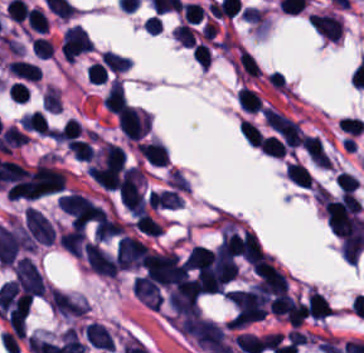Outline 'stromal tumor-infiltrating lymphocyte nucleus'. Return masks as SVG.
I'll use <instances>...</instances> for the list:
<instances>
[{"mask_svg":"<svg viewBox=\"0 0 364 353\" xmlns=\"http://www.w3.org/2000/svg\"><path fill=\"white\" fill-rule=\"evenodd\" d=\"M8 70L13 75L27 81L35 82L42 77L41 69L37 64L22 59L9 61Z\"/></svg>","mask_w":364,"mask_h":353,"instance_id":"4f13568d","label":"stromal tumor-infiltrating lymphocyte nucleus"},{"mask_svg":"<svg viewBox=\"0 0 364 353\" xmlns=\"http://www.w3.org/2000/svg\"><path fill=\"white\" fill-rule=\"evenodd\" d=\"M286 177L300 187L311 188L312 186V176L302 163L288 162Z\"/></svg>","mask_w":364,"mask_h":353,"instance_id":"2a367800","label":"stromal tumor-infiltrating lymphocyte nucleus"},{"mask_svg":"<svg viewBox=\"0 0 364 353\" xmlns=\"http://www.w3.org/2000/svg\"><path fill=\"white\" fill-rule=\"evenodd\" d=\"M172 34L186 47H193L196 43L195 31L187 23H180Z\"/></svg>","mask_w":364,"mask_h":353,"instance_id":"04cf8593","label":"stromal tumor-infiltrating lymphocyte nucleus"},{"mask_svg":"<svg viewBox=\"0 0 364 353\" xmlns=\"http://www.w3.org/2000/svg\"><path fill=\"white\" fill-rule=\"evenodd\" d=\"M123 229V223L101 209L95 226L96 240H105L123 234Z\"/></svg>","mask_w":364,"mask_h":353,"instance_id":"9ea309e8","label":"stromal tumor-infiltrating lymphocyte nucleus"},{"mask_svg":"<svg viewBox=\"0 0 364 353\" xmlns=\"http://www.w3.org/2000/svg\"><path fill=\"white\" fill-rule=\"evenodd\" d=\"M57 241L66 252L80 258L85 241V232L81 228L74 227L58 235Z\"/></svg>","mask_w":364,"mask_h":353,"instance_id":"f3e2335f","label":"stromal tumor-infiltrating lymphocyte nucleus"},{"mask_svg":"<svg viewBox=\"0 0 364 353\" xmlns=\"http://www.w3.org/2000/svg\"><path fill=\"white\" fill-rule=\"evenodd\" d=\"M93 43L82 26H69L65 32L61 48L66 61H75L91 50Z\"/></svg>","mask_w":364,"mask_h":353,"instance_id":"bc302bb0","label":"stromal tumor-infiltrating lymphocyte nucleus"},{"mask_svg":"<svg viewBox=\"0 0 364 353\" xmlns=\"http://www.w3.org/2000/svg\"><path fill=\"white\" fill-rule=\"evenodd\" d=\"M26 22L36 32H46L47 21L41 8L31 7L27 12Z\"/></svg>","mask_w":364,"mask_h":353,"instance_id":"42bb06b2","label":"stromal tumor-infiltrating lymphocyte nucleus"},{"mask_svg":"<svg viewBox=\"0 0 364 353\" xmlns=\"http://www.w3.org/2000/svg\"><path fill=\"white\" fill-rule=\"evenodd\" d=\"M145 258V247L140 240L123 236L117 243L115 260L119 268L132 270L139 268Z\"/></svg>","mask_w":364,"mask_h":353,"instance_id":"52c7bb5b","label":"stromal tumor-infiltrating lymphocyte nucleus"},{"mask_svg":"<svg viewBox=\"0 0 364 353\" xmlns=\"http://www.w3.org/2000/svg\"><path fill=\"white\" fill-rule=\"evenodd\" d=\"M215 253L211 249L195 247L191 249L185 266L187 271L206 272L214 267Z\"/></svg>","mask_w":364,"mask_h":353,"instance_id":"abfb95fc","label":"stromal tumor-infiltrating lymphocyte nucleus"},{"mask_svg":"<svg viewBox=\"0 0 364 353\" xmlns=\"http://www.w3.org/2000/svg\"><path fill=\"white\" fill-rule=\"evenodd\" d=\"M310 24L323 38L338 42L342 34V20L335 13H315Z\"/></svg>","mask_w":364,"mask_h":353,"instance_id":"3290ff9b","label":"stromal tumor-infiltrating lymphocyte nucleus"},{"mask_svg":"<svg viewBox=\"0 0 364 353\" xmlns=\"http://www.w3.org/2000/svg\"><path fill=\"white\" fill-rule=\"evenodd\" d=\"M261 150L272 157H283L285 145L274 135L263 137L259 143Z\"/></svg>","mask_w":364,"mask_h":353,"instance_id":"3c572f05","label":"stromal tumor-infiltrating lymphocyte nucleus"},{"mask_svg":"<svg viewBox=\"0 0 364 353\" xmlns=\"http://www.w3.org/2000/svg\"><path fill=\"white\" fill-rule=\"evenodd\" d=\"M240 128L250 144L259 146L263 133L256 123L243 118Z\"/></svg>","mask_w":364,"mask_h":353,"instance_id":"9e4306bb","label":"stromal tumor-infiltrating lymphocyte nucleus"},{"mask_svg":"<svg viewBox=\"0 0 364 353\" xmlns=\"http://www.w3.org/2000/svg\"><path fill=\"white\" fill-rule=\"evenodd\" d=\"M235 67L249 77H260L259 66L252 54L239 47Z\"/></svg>","mask_w":364,"mask_h":353,"instance_id":"4803ca6d","label":"stromal tumor-infiltrating lymphocyte nucleus"},{"mask_svg":"<svg viewBox=\"0 0 364 353\" xmlns=\"http://www.w3.org/2000/svg\"><path fill=\"white\" fill-rule=\"evenodd\" d=\"M101 61L103 65L117 72L126 71L127 69H129L130 65L128 57L114 53L109 50L101 54Z\"/></svg>","mask_w":364,"mask_h":353,"instance_id":"4c9ddf68","label":"stromal tumor-infiltrating lymphocyte nucleus"},{"mask_svg":"<svg viewBox=\"0 0 364 353\" xmlns=\"http://www.w3.org/2000/svg\"><path fill=\"white\" fill-rule=\"evenodd\" d=\"M238 104L242 110H248L255 113L261 111V98L254 90L244 86L238 95Z\"/></svg>","mask_w":364,"mask_h":353,"instance_id":"4245b91a","label":"stromal tumor-infiltrating lymphocyte nucleus"},{"mask_svg":"<svg viewBox=\"0 0 364 353\" xmlns=\"http://www.w3.org/2000/svg\"><path fill=\"white\" fill-rule=\"evenodd\" d=\"M183 23H198L202 21L205 10L197 2L185 1L181 4Z\"/></svg>","mask_w":364,"mask_h":353,"instance_id":"2761f720","label":"stromal tumor-infiltrating lymphocyte nucleus"}]
</instances>
